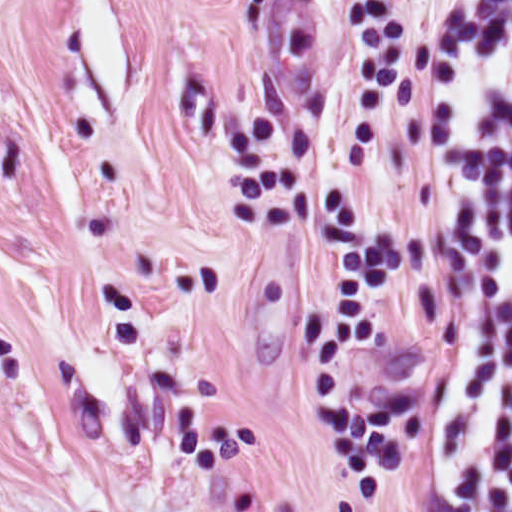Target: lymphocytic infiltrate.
I'll return each mask as SVG.
<instances>
[{"instance_id":"obj_1","label":"lymphocytic infiltrate","mask_w":512,"mask_h":512,"mask_svg":"<svg viewBox=\"0 0 512 512\" xmlns=\"http://www.w3.org/2000/svg\"><path fill=\"white\" fill-rule=\"evenodd\" d=\"M428 165L440 270L416 370L444 512H512V0H439Z\"/></svg>"}]
</instances>
